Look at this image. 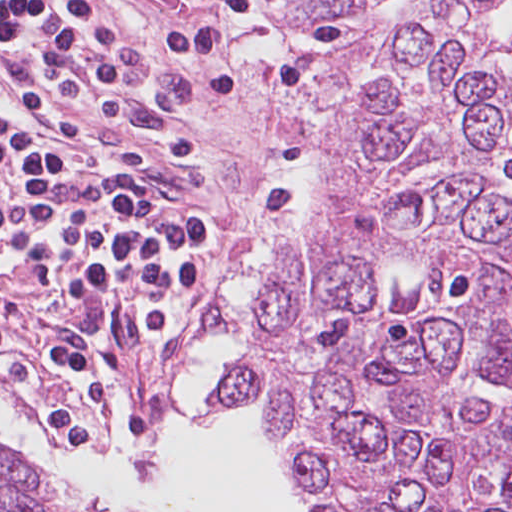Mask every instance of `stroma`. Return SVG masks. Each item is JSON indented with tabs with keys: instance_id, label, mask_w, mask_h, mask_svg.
<instances>
[{
	"instance_id": "stroma-1",
	"label": "stroma",
	"mask_w": 512,
	"mask_h": 512,
	"mask_svg": "<svg viewBox=\"0 0 512 512\" xmlns=\"http://www.w3.org/2000/svg\"><path fill=\"white\" fill-rule=\"evenodd\" d=\"M96 1L127 40L136 94L162 121L76 124L92 138H183L193 143L207 165L200 200L217 228L211 305L224 275L229 243L269 222L276 175L297 168L305 178V193L290 210L266 283L275 271L284 239L320 181L348 72L400 20L444 0H383L369 9H337L326 15H282L270 0H256L287 53L288 78L281 87L215 92L190 88L181 77L180 14L161 0ZM46 316L72 329L96 358L106 376V395L120 393L130 404L128 388L97 333L70 316L42 309L27 272L11 262L0 273V337L5 343L0 371L22 400L2 384L0 393L19 401L49 431L48 423L59 409L70 410L84 427L93 425L54 363ZM191 378L190 360L179 388ZM251 408L265 412L261 403L236 410ZM6 455L12 471L41 490L28 471L7 451Z\"/></svg>"
}]
</instances>
